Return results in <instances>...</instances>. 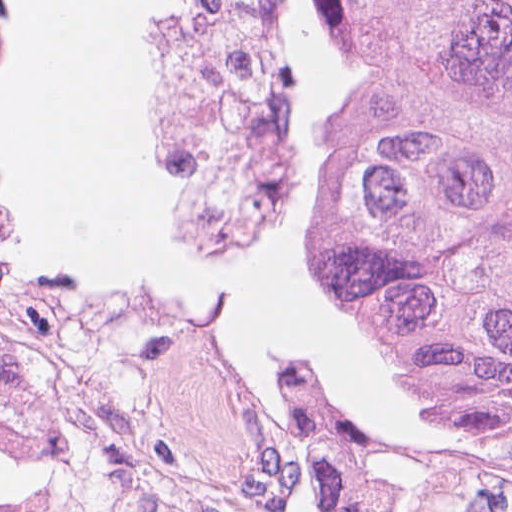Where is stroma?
Here are the masks:
<instances>
[{"label": "stroma", "instance_id": "obj_1", "mask_svg": "<svg viewBox=\"0 0 512 512\" xmlns=\"http://www.w3.org/2000/svg\"><path fill=\"white\" fill-rule=\"evenodd\" d=\"M337 49V0H316ZM277 33L286 54L289 0ZM2 56V55H0ZM15 57V56H5ZM321 247L328 251L323 215ZM0 320L65 369L113 361L133 369L185 424L300 491L314 512H512V453L447 461L390 450L376 418L303 364L281 394L214 348L191 317L116 300H70L21 267L0 222ZM56 402L0 411L55 414Z\"/></svg>", "mask_w": 512, "mask_h": 512}]
</instances>
